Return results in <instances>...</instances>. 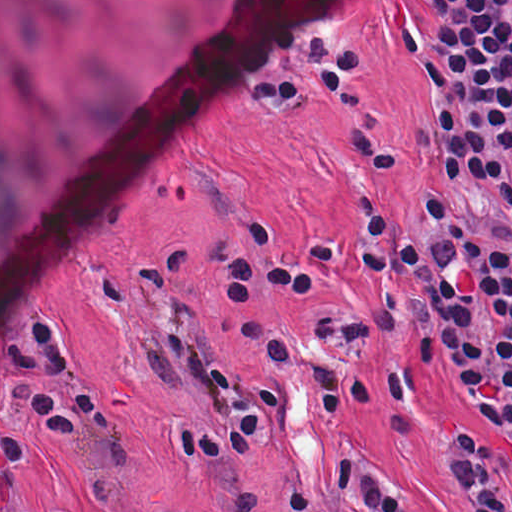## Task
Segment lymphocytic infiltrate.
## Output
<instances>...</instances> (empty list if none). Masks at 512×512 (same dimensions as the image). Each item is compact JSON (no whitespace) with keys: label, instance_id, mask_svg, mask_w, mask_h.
Masks as SVG:
<instances>
[{"label":"lymphocytic infiltrate","instance_id":"f902f5d3","mask_svg":"<svg viewBox=\"0 0 512 512\" xmlns=\"http://www.w3.org/2000/svg\"><path fill=\"white\" fill-rule=\"evenodd\" d=\"M430 230L420 245L381 213L360 216L357 255L370 304L354 316L333 308L319 320L327 337L371 341L409 333L413 361L396 371L336 368L303 345L292 329L242 316L235 342L257 348L267 365L304 374L337 418L359 396L392 398L409 432L428 399V364L439 353L457 383L500 423L491 436L479 421L441 431V465L454 478L470 512H512V147L413 192ZM338 242H313L278 260L270 276L225 281L233 297L281 291L313 294L339 270ZM197 289L158 306L178 356L221 398L212 427L166 424L182 452L214 465H251L278 439L284 407L267 389L241 378L218 354L196 320ZM286 512H414L388 476L363 457L337 452L319 489L291 479L281 490Z\"/></svg>","mask_w":512,"mask_h":512}]
</instances>
